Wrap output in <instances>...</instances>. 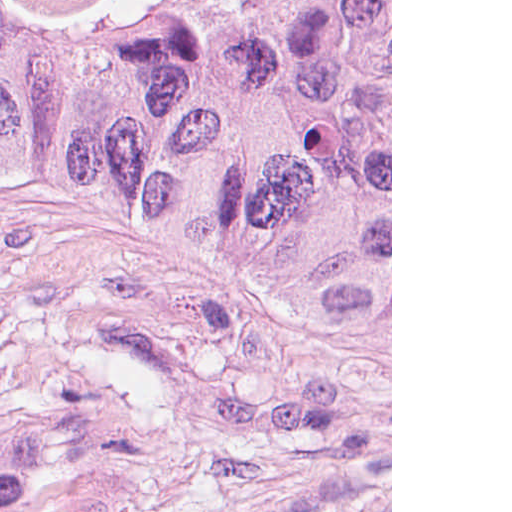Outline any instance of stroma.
Wrapping results in <instances>:
<instances>
[{
	"label": "stroma",
	"mask_w": 512,
	"mask_h": 512,
	"mask_svg": "<svg viewBox=\"0 0 512 512\" xmlns=\"http://www.w3.org/2000/svg\"><path fill=\"white\" fill-rule=\"evenodd\" d=\"M0 357L54 388L120 363L161 378V435L122 512H392V0L390 371L237 340L148 254L2 211Z\"/></svg>",
	"instance_id": "obj_1"
}]
</instances>
